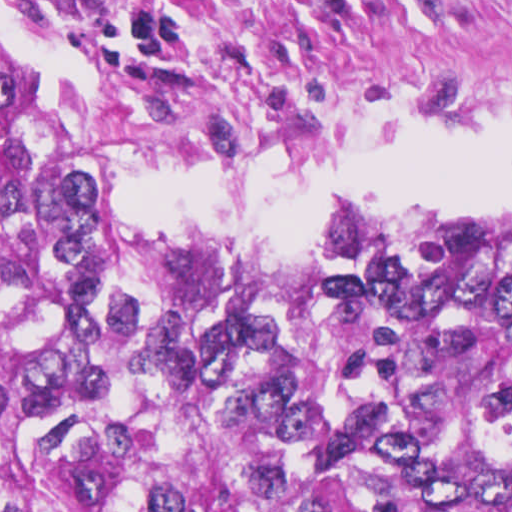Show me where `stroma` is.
<instances>
[{
	"label": "stroma",
	"mask_w": 512,
	"mask_h": 512,
	"mask_svg": "<svg viewBox=\"0 0 512 512\" xmlns=\"http://www.w3.org/2000/svg\"><path fill=\"white\" fill-rule=\"evenodd\" d=\"M0 58L47 96L46 167L100 196L141 162L264 154L419 98L512 103V0H175L124 34L61 0H0ZM125 212L232 253H402L492 235L228 238Z\"/></svg>",
	"instance_id": "35a3bbf8"
}]
</instances>
